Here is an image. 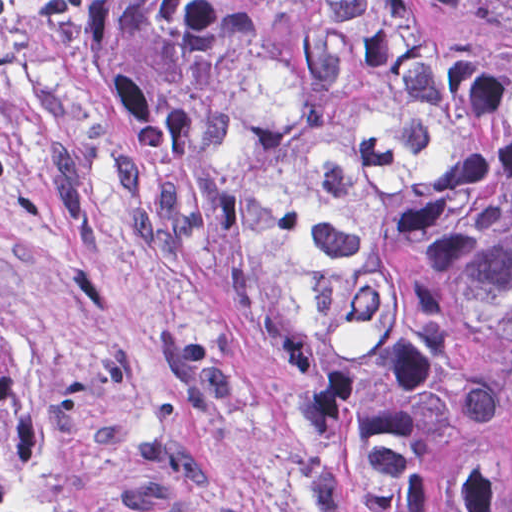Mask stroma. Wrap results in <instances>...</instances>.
Here are the masks:
<instances>
[{"mask_svg": "<svg viewBox=\"0 0 512 512\" xmlns=\"http://www.w3.org/2000/svg\"><path fill=\"white\" fill-rule=\"evenodd\" d=\"M512 24V0H423ZM101 0L1 33L0 328L50 435L129 512H311L290 463L294 349L206 213L90 64Z\"/></svg>", "mask_w": 512, "mask_h": 512, "instance_id": "35a3bbf8", "label": "stroma"}]
</instances>
